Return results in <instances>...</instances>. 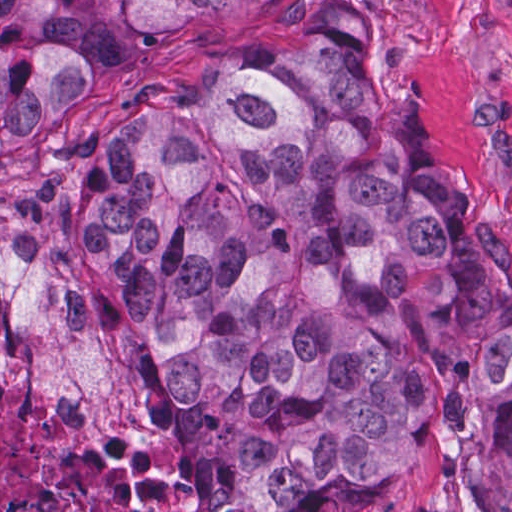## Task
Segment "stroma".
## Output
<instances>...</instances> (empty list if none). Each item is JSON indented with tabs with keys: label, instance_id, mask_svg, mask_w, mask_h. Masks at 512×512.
Wrapping results in <instances>:
<instances>
[{
	"label": "stroma",
	"instance_id": "1",
	"mask_svg": "<svg viewBox=\"0 0 512 512\" xmlns=\"http://www.w3.org/2000/svg\"><path fill=\"white\" fill-rule=\"evenodd\" d=\"M0 1H234L106 69L59 120L0 157V377H51L143 440L169 480L191 489V512L205 504L152 367L129 335L92 311L101 291L68 236L84 219L101 138L156 93L257 61L317 25L380 35L455 202L479 242L512 258V0ZM329 512L512 510H496L463 477L443 418L427 454Z\"/></svg>",
	"mask_w": 512,
	"mask_h": 512
}]
</instances>
